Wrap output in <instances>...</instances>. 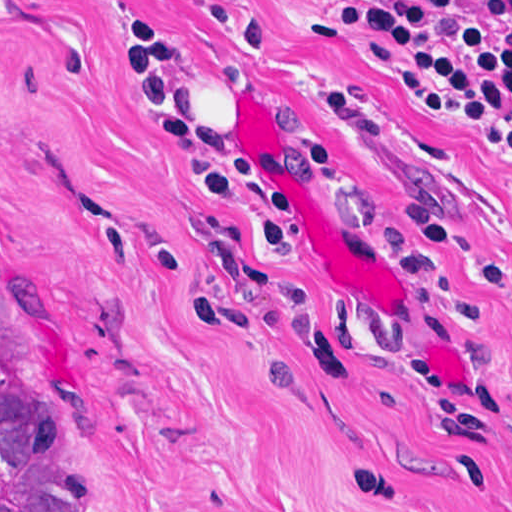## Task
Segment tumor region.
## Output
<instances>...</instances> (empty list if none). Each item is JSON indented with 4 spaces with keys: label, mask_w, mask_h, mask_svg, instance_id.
Instances as JSON below:
<instances>
[{
    "label": "tumor region",
    "mask_w": 512,
    "mask_h": 512,
    "mask_svg": "<svg viewBox=\"0 0 512 512\" xmlns=\"http://www.w3.org/2000/svg\"><path fill=\"white\" fill-rule=\"evenodd\" d=\"M0 512H103L74 430L27 374L5 376L1 354Z\"/></svg>",
    "instance_id": "tumor-region-1"
}]
</instances>
